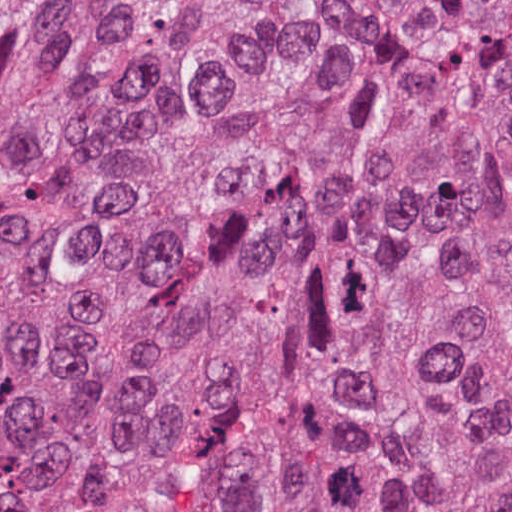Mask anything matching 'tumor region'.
Masks as SVG:
<instances>
[{
  "mask_svg": "<svg viewBox=\"0 0 512 512\" xmlns=\"http://www.w3.org/2000/svg\"><path fill=\"white\" fill-rule=\"evenodd\" d=\"M0 512H512V0H0Z\"/></svg>",
  "mask_w": 512,
  "mask_h": 512,
  "instance_id": "tumor-region-1",
  "label": "tumor region"
}]
</instances>
